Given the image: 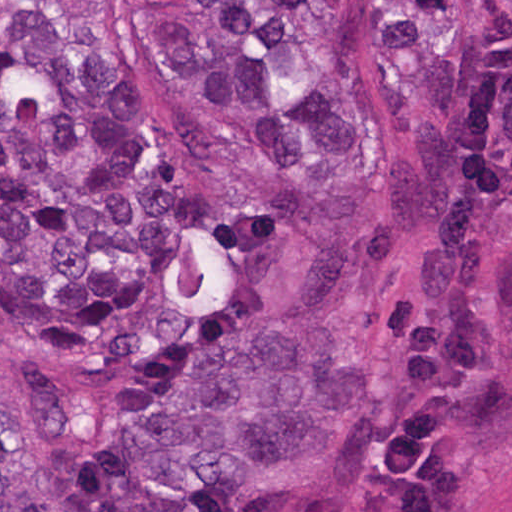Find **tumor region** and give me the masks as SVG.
Instances as JSON below:
<instances>
[{
  "mask_svg": "<svg viewBox=\"0 0 512 512\" xmlns=\"http://www.w3.org/2000/svg\"><path fill=\"white\" fill-rule=\"evenodd\" d=\"M247 181L194 183L81 47L0 29V512H293L434 224L478 0H145Z\"/></svg>",
  "mask_w": 512,
  "mask_h": 512,
  "instance_id": "obj_1",
  "label": "tumor region"
}]
</instances>
